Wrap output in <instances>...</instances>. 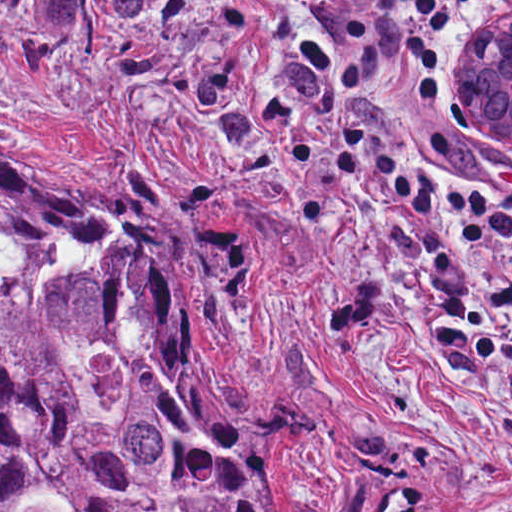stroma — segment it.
<instances>
[{"instance_id":"35a3bbf8","label":"stroma","mask_w":512,"mask_h":512,"mask_svg":"<svg viewBox=\"0 0 512 512\" xmlns=\"http://www.w3.org/2000/svg\"><path fill=\"white\" fill-rule=\"evenodd\" d=\"M511 7L460 14L432 103L383 95L421 174L512 193V142L459 117ZM0 162L135 189L209 255V400L282 512H512V279L342 170L269 0H0Z\"/></svg>"}]
</instances>
